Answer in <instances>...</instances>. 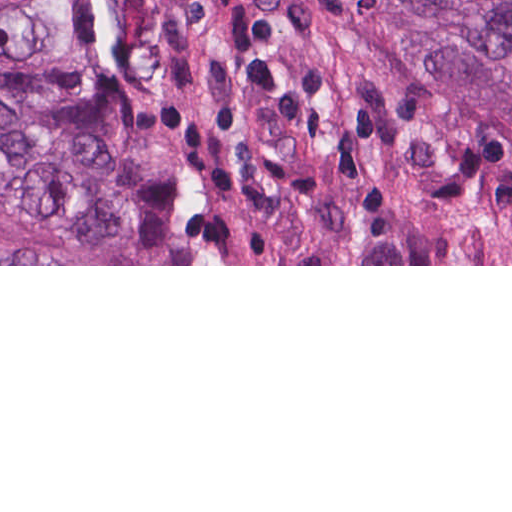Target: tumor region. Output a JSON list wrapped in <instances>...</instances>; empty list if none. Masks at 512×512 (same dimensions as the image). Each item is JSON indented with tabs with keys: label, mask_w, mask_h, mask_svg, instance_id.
<instances>
[{
	"label": "tumor region",
	"mask_w": 512,
	"mask_h": 512,
	"mask_svg": "<svg viewBox=\"0 0 512 512\" xmlns=\"http://www.w3.org/2000/svg\"><path fill=\"white\" fill-rule=\"evenodd\" d=\"M407 47L512 136V0H383ZM88 0H0V51L74 63ZM0 232L57 264H135L105 112L63 77L0 63Z\"/></svg>",
	"instance_id": "tumor-region-1"
}]
</instances>
